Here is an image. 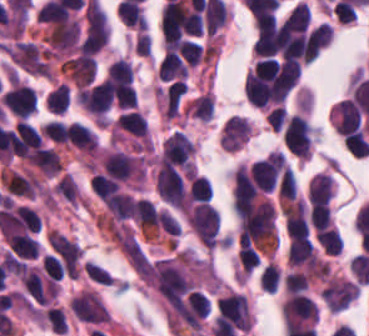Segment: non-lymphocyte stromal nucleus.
I'll return each instance as SVG.
<instances>
[{"label": "non-lymphocyte stromal nucleus", "instance_id": "dd21d789", "mask_svg": "<svg viewBox=\"0 0 369 336\" xmlns=\"http://www.w3.org/2000/svg\"><path fill=\"white\" fill-rule=\"evenodd\" d=\"M189 229L205 248L211 249L219 240V217L211 205L194 203L185 214Z\"/></svg>", "mask_w": 369, "mask_h": 336}, {"label": "non-lymphocyte stromal nucleus", "instance_id": "a72fc3eb", "mask_svg": "<svg viewBox=\"0 0 369 336\" xmlns=\"http://www.w3.org/2000/svg\"><path fill=\"white\" fill-rule=\"evenodd\" d=\"M46 258L65 269H76L81 252L75 241L56 229L45 234Z\"/></svg>", "mask_w": 369, "mask_h": 336}, {"label": "non-lymphocyte stromal nucleus", "instance_id": "3746e769", "mask_svg": "<svg viewBox=\"0 0 369 336\" xmlns=\"http://www.w3.org/2000/svg\"><path fill=\"white\" fill-rule=\"evenodd\" d=\"M71 313L88 323H107L110 318L96 290L83 289L69 300Z\"/></svg>", "mask_w": 369, "mask_h": 336}, {"label": "non-lymphocyte stromal nucleus", "instance_id": "fc2b8d12", "mask_svg": "<svg viewBox=\"0 0 369 336\" xmlns=\"http://www.w3.org/2000/svg\"><path fill=\"white\" fill-rule=\"evenodd\" d=\"M329 310H342L358 296V283L344 277L330 275L319 292Z\"/></svg>", "mask_w": 369, "mask_h": 336}, {"label": "non-lymphocyte stromal nucleus", "instance_id": "81446118", "mask_svg": "<svg viewBox=\"0 0 369 336\" xmlns=\"http://www.w3.org/2000/svg\"><path fill=\"white\" fill-rule=\"evenodd\" d=\"M51 51L70 53L79 38V24L74 17L56 21L44 36Z\"/></svg>", "mask_w": 369, "mask_h": 336}, {"label": "non-lymphocyte stromal nucleus", "instance_id": "7c5642bf", "mask_svg": "<svg viewBox=\"0 0 369 336\" xmlns=\"http://www.w3.org/2000/svg\"><path fill=\"white\" fill-rule=\"evenodd\" d=\"M73 85L82 86L92 81L96 63L91 54L79 52L68 57L60 65Z\"/></svg>", "mask_w": 369, "mask_h": 336}]
</instances>
